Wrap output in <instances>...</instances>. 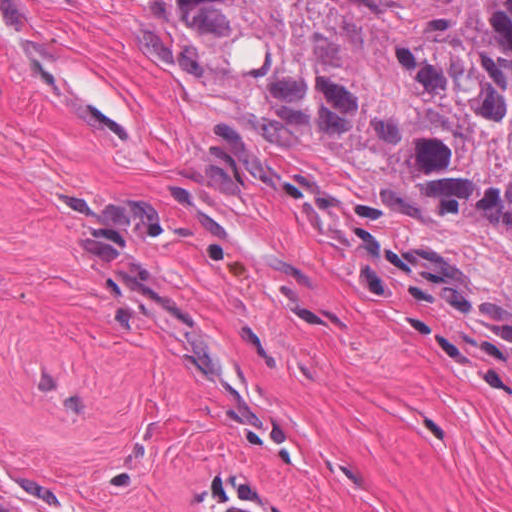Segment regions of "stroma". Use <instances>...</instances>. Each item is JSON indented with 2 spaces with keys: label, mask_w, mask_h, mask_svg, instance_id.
Instances as JSON below:
<instances>
[{
  "label": "stroma",
  "mask_w": 512,
  "mask_h": 512,
  "mask_svg": "<svg viewBox=\"0 0 512 512\" xmlns=\"http://www.w3.org/2000/svg\"><path fill=\"white\" fill-rule=\"evenodd\" d=\"M175 0L0 25V507L512 512V231L268 113Z\"/></svg>",
  "instance_id": "35a3bbf8"
}]
</instances>
